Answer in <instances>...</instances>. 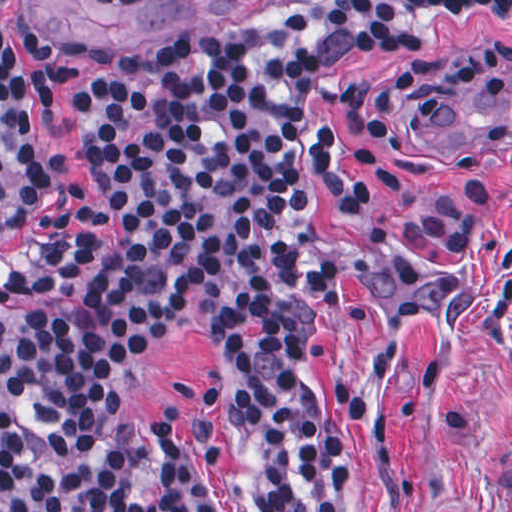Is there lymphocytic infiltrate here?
Wrapping results in <instances>:
<instances>
[{
    "label": "lymphocytic infiltrate",
    "instance_id": "f902f5d3",
    "mask_svg": "<svg viewBox=\"0 0 512 512\" xmlns=\"http://www.w3.org/2000/svg\"><path fill=\"white\" fill-rule=\"evenodd\" d=\"M0 0V241L46 207L37 111L55 88L18 55ZM129 0H100L104 4ZM512 0H343L258 27L146 44L85 43L100 67L73 105L95 190L42 216L0 278V512H96L149 477L132 341L182 307H217L273 389L274 512H336L333 423L308 384L328 296L314 203L375 205L373 146L320 105L326 71L432 39L416 11Z\"/></svg>",
    "mask_w": 512,
    "mask_h": 512
}]
</instances>
